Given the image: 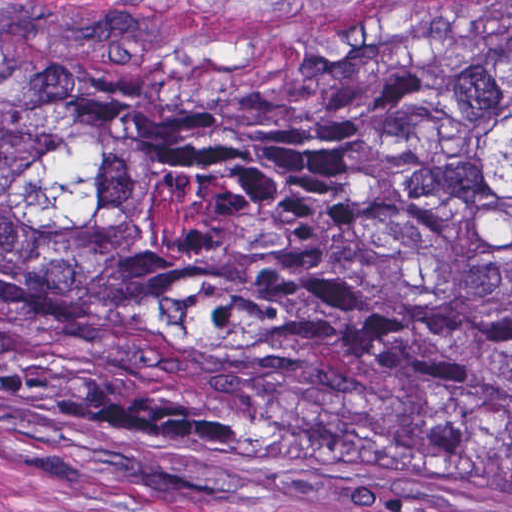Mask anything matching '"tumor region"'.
Here are the masks:
<instances>
[{
	"mask_svg": "<svg viewBox=\"0 0 512 512\" xmlns=\"http://www.w3.org/2000/svg\"><path fill=\"white\" fill-rule=\"evenodd\" d=\"M0 388L191 458L512 465V34L149 67L0 33Z\"/></svg>",
	"mask_w": 512,
	"mask_h": 512,
	"instance_id": "1",
	"label": "tumor region"
}]
</instances>
